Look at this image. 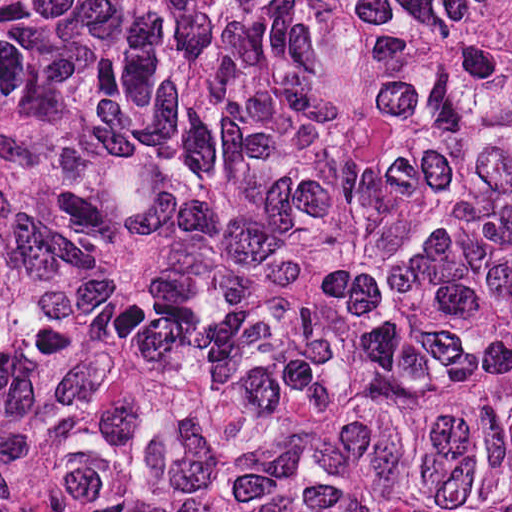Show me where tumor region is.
<instances>
[{
	"label": "tumor region",
	"instance_id": "1",
	"mask_svg": "<svg viewBox=\"0 0 512 512\" xmlns=\"http://www.w3.org/2000/svg\"><path fill=\"white\" fill-rule=\"evenodd\" d=\"M0 512H512V0H0Z\"/></svg>",
	"mask_w": 512,
	"mask_h": 512
}]
</instances>
